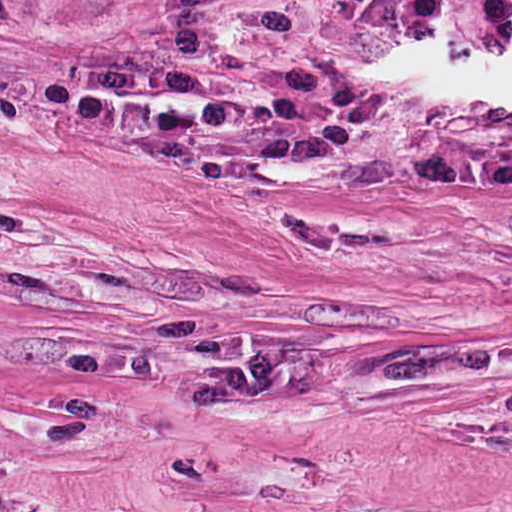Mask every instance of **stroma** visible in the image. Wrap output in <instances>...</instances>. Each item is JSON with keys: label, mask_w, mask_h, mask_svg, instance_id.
Returning a JSON list of instances; mask_svg holds the SVG:
<instances>
[{"label": "stroma", "mask_w": 512, "mask_h": 512, "mask_svg": "<svg viewBox=\"0 0 512 512\" xmlns=\"http://www.w3.org/2000/svg\"><path fill=\"white\" fill-rule=\"evenodd\" d=\"M0 512H512V0H0Z\"/></svg>", "instance_id": "1"}]
</instances>
